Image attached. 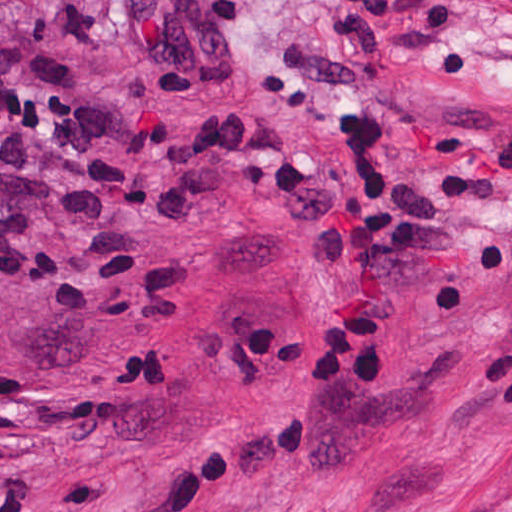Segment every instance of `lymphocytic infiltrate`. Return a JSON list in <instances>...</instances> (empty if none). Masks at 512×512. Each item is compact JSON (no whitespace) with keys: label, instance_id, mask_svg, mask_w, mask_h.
Wrapping results in <instances>:
<instances>
[{"label":"lymphocytic infiltrate","instance_id":"lymphocytic-infiltrate-1","mask_svg":"<svg viewBox=\"0 0 512 512\" xmlns=\"http://www.w3.org/2000/svg\"><path fill=\"white\" fill-rule=\"evenodd\" d=\"M246 0H124L129 30L167 96H194L241 75L236 27ZM470 0H324L315 40L279 37L265 105L292 110L329 137L349 172L312 161L272 125L232 122L180 151V167L283 224L315 248H333V300L309 352L318 386L376 393L391 381L411 256L439 252L456 205L402 171V105L375 95V69L398 63L440 78L478 75L472 43H449ZM512 168V138L488 147Z\"/></svg>","mask_w":512,"mask_h":512}]
</instances>
